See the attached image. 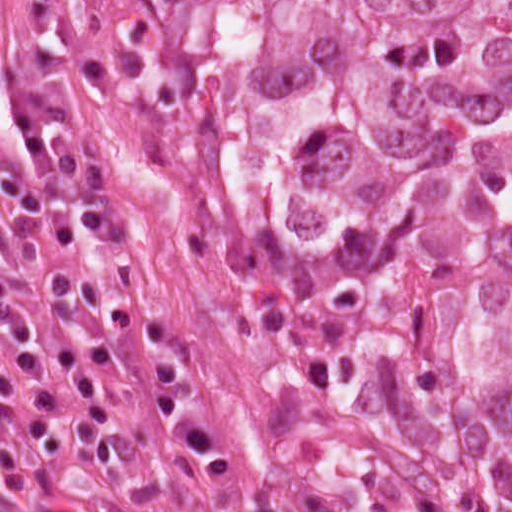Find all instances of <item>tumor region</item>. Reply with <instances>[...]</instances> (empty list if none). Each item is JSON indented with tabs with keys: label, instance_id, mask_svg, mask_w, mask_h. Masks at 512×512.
<instances>
[{
	"label": "tumor region",
	"instance_id": "1",
	"mask_svg": "<svg viewBox=\"0 0 512 512\" xmlns=\"http://www.w3.org/2000/svg\"><path fill=\"white\" fill-rule=\"evenodd\" d=\"M295 512H512V0H95Z\"/></svg>",
	"mask_w": 512,
	"mask_h": 512
}]
</instances>
